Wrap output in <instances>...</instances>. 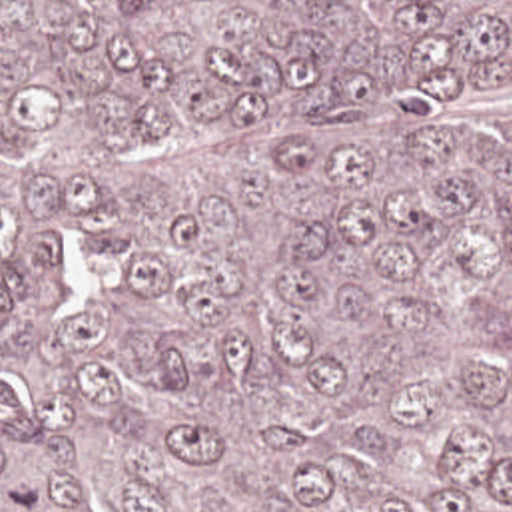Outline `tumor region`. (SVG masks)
I'll use <instances>...</instances> for the list:
<instances>
[{
    "label": "tumor region",
    "mask_w": 512,
    "mask_h": 512,
    "mask_svg": "<svg viewBox=\"0 0 512 512\" xmlns=\"http://www.w3.org/2000/svg\"><path fill=\"white\" fill-rule=\"evenodd\" d=\"M0 512H512V0H0Z\"/></svg>",
    "instance_id": "tumor-region-1"
}]
</instances>
